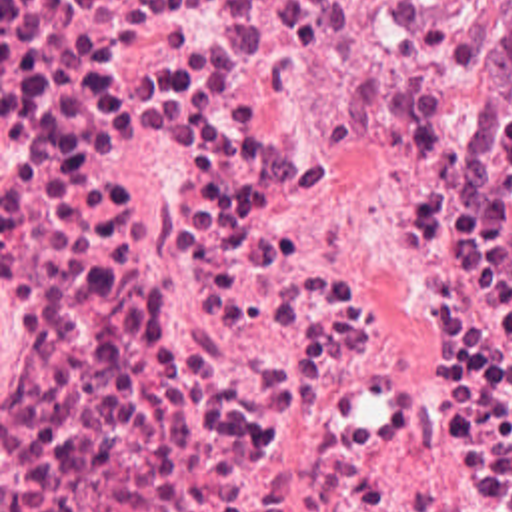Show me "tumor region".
<instances>
[{
  "label": "tumor region",
  "mask_w": 512,
  "mask_h": 512,
  "mask_svg": "<svg viewBox=\"0 0 512 512\" xmlns=\"http://www.w3.org/2000/svg\"><path fill=\"white\" fill-rule=\"evenodd\" d=\"M494 75L512 99V0H492Z\"/></svg>",
  "instance_id": "obj_1"
}]
</instances>
